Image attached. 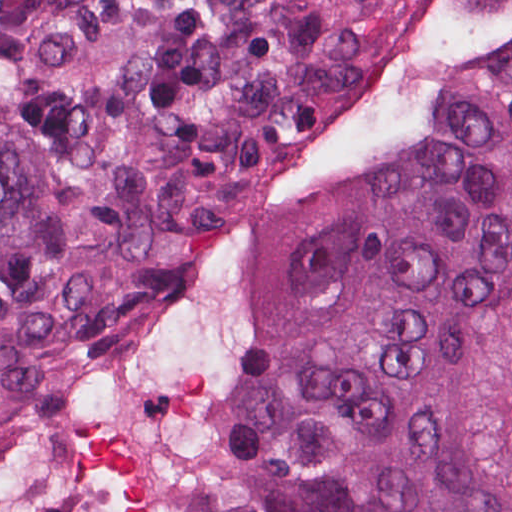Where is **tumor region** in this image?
Segmentation results:
<instances>
[{"label": "tumor region", "mask_w": 512, "mask_h": 512, "mask_svg": "<svg viewBox=\"0 0 512 512\" xmlns=\"http://www.w3.org/2000/svg\"><path fill=\"white\" fill-rule=\"evenodd\" d=\"M373 0H0V422L265 170ZM227 512H512V52L259 286Z\"/></svg>", "instance_id": "e687c5a6"}]
</instances>
